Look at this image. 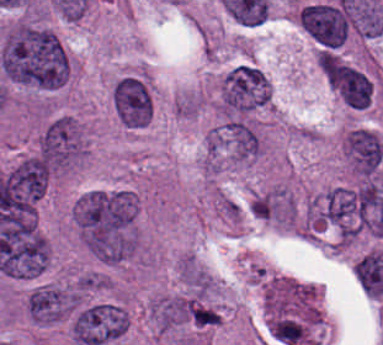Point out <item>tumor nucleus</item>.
Wrapping results in <instances>:
<instances>
[{"instance_id": "1", "label": "tumor nucleus", "mask_w": 383, "mask_h": 345, "mask_svg": "<svg viewBox=\"0 0 383 345\" xmlns=\"http://www.w3.org/2000/svg\"><path fill=\"white\" fill-rule=\"evenodd\" d=\"M0 66L11 81L47 90L65 82L69 74V58L57 34L25 22L5 33Z\"/></svg>"}, {"instance_id": "2", "label": "tumor nucleus", "mask_w": 383, "mask_h": 345, "mask_svg": "<svg viewBox=\"0 0 383 345\" xmlns=\"http://www.w3.org/2000/svg\"><path fill=\"white\" fill-rule=\"evenodd\" d=\"M304 227L348 240L358 234L353 186L335 185L310 199Z\"/></svg>"}, {"instance_id": "3", "label": "tumor nucleus", "mask_w": 383, "mask_h": 345, "mask_svg": "<svg viewBox=\"0 0 383 345\" xmlns=\"http://www.w3.org/2000/svg\"><path fill=\"white\" fill-rule=\"evenodd\" d=\"M85 150L83 130L73 116L48 118L37 137L36 156L55 170L77 164Z\"/></svg>"}, {"instance_id": "4", "label": "tumor nucleus", "mask_w": 383, "mask_h": 345, "mask_svg": "<svg viewBox=\"0 0 383 345\" xmlns=\"http://www.w3.org/2000/svg\"><path fill=\"white\" fill-rule=\"evenodd\" d=\"M273 87L266 73L254 64L241 63L227 72L221 102L229 117L251 113L269 105Z\"/></svg>"}, {"instance_id": "5", "label": "tumor nucleus", "mask_w": 383, "mask_h": 345, "mask_svg": "<svg viewBox=\"0 0 383 345\" xmlns=\"http://www.w3.org/2000/svg\"><path fill=\"white\" fill-rule=\"evenodd\" d=\"M130 323L126 306L112 301L93 302L76 313L71 332L83 345H100L122 337Z\"/></svg>"}, {"instance_id": "6", "label": "tumor nucleus", "mask_w": 383, "mask_h": 345, "mask_svg": "<svg viewBox=\"0 0 383 345\" xmlns=\"http://www.w3.org/2000/svg\"><path fill=\"white\" fill-rule=\"evenodd\" d=\"M299 23L324 49H337L351 29L352 16L341 0L315 1L302 6Z\"/></svg>"}, {"instance_id": "7", "label": "tumor nucleus", "mask_w": 383, "mask_h": 345, "mask_svg": "<svg viewBox=\"0 0 383 345\" xmlns=\"http://www.w3.org/2000/svg\"><path fill=\"white\" fill-rule=\"evenodd\" d=\"M77 284L35 285L28 293L26 311L32 321L54 323L68 316L79 304Z\"/></svg>"}, {"instance_id": "8", "label": "tumor nucleus", "mask_w": 383, "mask_h": 345, "mask_svg": "<svg viewBox=\"0 0 383 345\" xmlns=\"http://www.w3.org/2000/svg\"><path fill=\"white\" fill-rule=\"evenodd\" d=\"M342 154L357 175L379 170L383 162V142L372 130L352 127L342 136Z\"/></svg>"}, {"instance_id": "9", "label": "tumor nucleus", "mask_w": 383, "mask_h": 345, "mask_svg": "<svg viewBox=\"0 0 383 345\" xmlns=\"http://www.w3.org/2000/svg\"><path fill=\"white\" fill-rule=\"evenodd\" d=\"M251 212L261 218L288 223L295 216L294 199L288 190H268L253 196Z\"/></svg>"}, {"instance_id": "10", "label": "tumor nucleus", "mask_w": 383, "mask_h": 345, "mask_svg": "<svg viewBox=\"0 0 383 345\" xmlns=\"http://www.w3.org/2000/svg\"><path fill=\"white\" fill-rule=\"evenodd\" d=\"M195 302L191 296L171 295L151 303L150 312L162 329H170L189 320Z\"/></svg>"}]
</instances>
